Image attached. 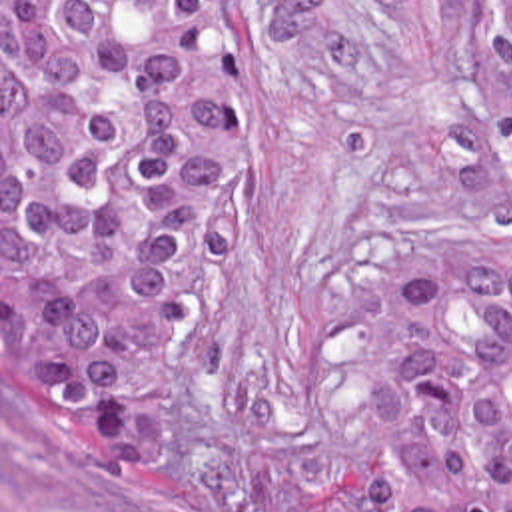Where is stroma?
Here are the masks:
<instances>
[{
    "label": "stroma",
    "mask_w": 512,
    "mask_h": 512,
    "mask_svg": "<svg viewBox=\"0 0 512 512\" xmlns=\"http://www.w3.org/2000/svg\"><path fill=\"white\" fill-rule=\"evenodd\" d=\"M469 246H512L481 0H256V170L190 302L174 436L128 477L78 467L2 394L0 0V512H373L383 266Z\"/></svg>",
    "instance_id": "obj_1"
}]
</instances>
